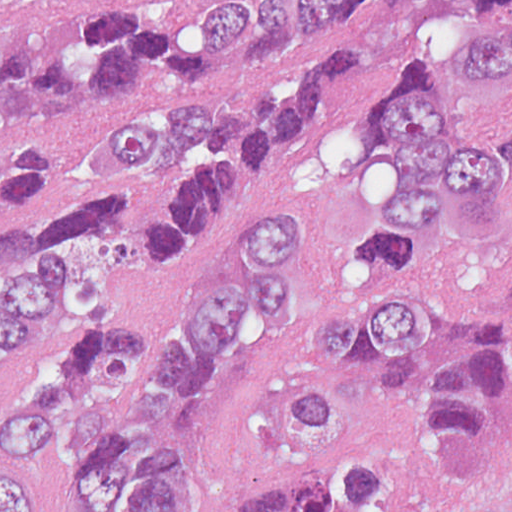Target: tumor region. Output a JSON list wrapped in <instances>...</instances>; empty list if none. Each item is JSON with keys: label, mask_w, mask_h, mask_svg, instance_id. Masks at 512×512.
Segmentation results:
<instances>
[{"label": "tumor region", "mask_w": 512, "mask_h": 512, "mask_svg": "<svg viewBox=\"0 0 512 512\" xmlns=\"http://www.w3.org/2000/svg\"><path fill=\"white\" fill-rule=\"evenodd\" d=\"M262 1H0V100L63 127L136 65L202 80ZM362 22L385 75L365 144L385 177L270 419L282 454L247 512H512V1H298ZM354 33L245 84H154L104 119L78 200L44 136L0 161V512H201L210 425L298 309L313 222L288 207L174 291L155 245L240 224Z\"/></svg>", "instance_id": "e687c5a6"}]
</instances>
